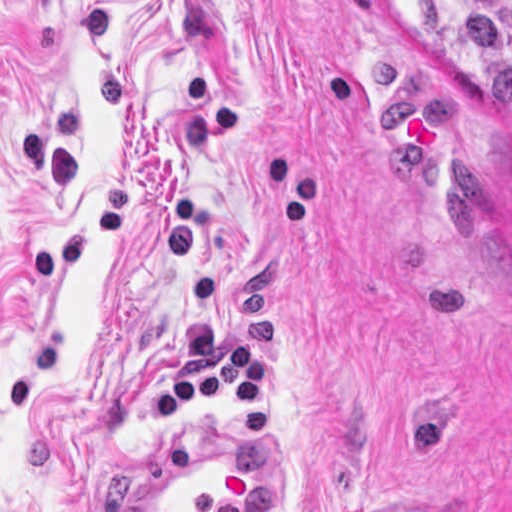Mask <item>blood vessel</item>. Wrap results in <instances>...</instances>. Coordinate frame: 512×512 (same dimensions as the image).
Segmentation results:
<instances>
[{"mask_svg":"<svg viewBox=\"0 0 512 512\" xmlns=\"http://www.w3.org/2000/svg\"><path fill=\"white\" fill-rule=\"evenodd\" d=\"M212 420L144 456L129 512H281L276 469L233 423Z\"/></svg>","mask_w":512,"mask_h":512,"instance_id":"obj_1","label":"blood vessel"}]
</instances>
